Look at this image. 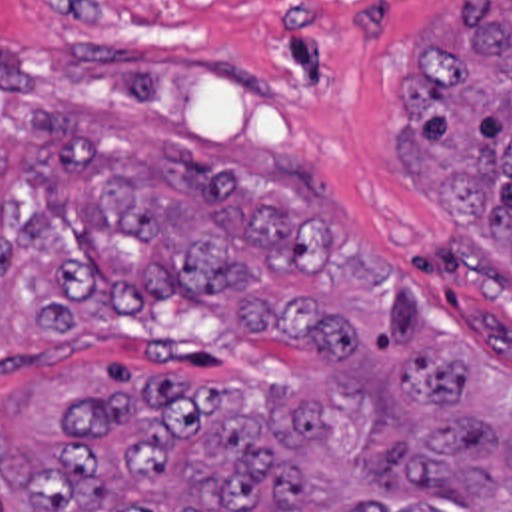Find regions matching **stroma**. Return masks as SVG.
<instances>
[{
  "label": "stroma",
  "mask_w": 512,
  "mask_h": 512,
  "mask_svg": "<svg viewBox=\"0 0 512 512\" xmlns=\"http://www.w3.org/2000/svg\"><path fill=\"white\" fill-rule=\"evenodd\" d=\"M465 0H251L183 13L42 11L0 0V123L60 109L121 135L185 145L225 171L307 161L337 189V215L403 285L427 331L512 377V261L431 215L397 153L399 85ZM341 203V205H339ZM64 371L173 375L281 397L297 351L233 335L165 299L75 339H0V401Z\"/></svg>",
  "instance_id": "obj_1"
}]
</instances>
